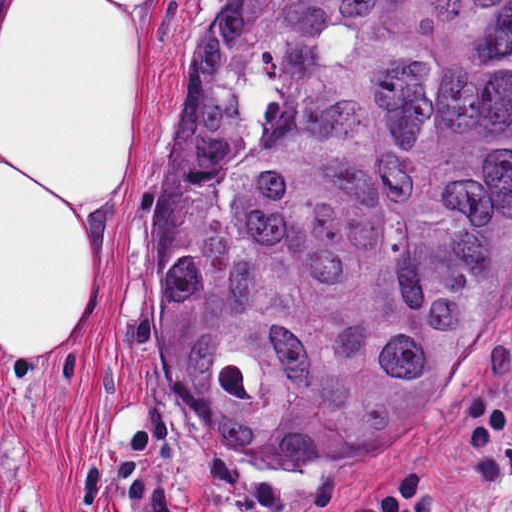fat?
<instances>
[{
	"mask_svg": "<svg viewBox=\"0 0 512 512\" xmlns=\"http://www.w3.org/2000/svg\"><path fill=\"white\" fill-rule=\"evenodd\" d=\"M178 0H29L0 66V360H58L100 312Z\"/></svg>",
	"mask_w": 512,
	"mask_h": 512,
	"instance_id": "53f6f03d",
	"label": "fat"
}]
</instances>
